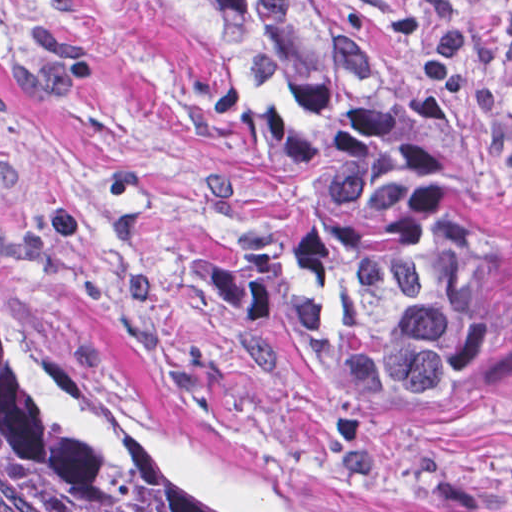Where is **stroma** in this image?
<instances>
[{
  "label": "stroma",
  "instance_id": "stroma-1",
  "mask_svg": "<svg viewBox=\"0 0 512 512\" xmlns=\"http://www.w3.org/2000/svg\"><path fill=\"white\" fill-rule=\"evenodd\" d=\"M323 1L512 269V0ZM243 58L208 0H0V265L38 364L215 512H512V378L402 435L281 311L312 221L217 123Z\"/></svg>",
  "mask_w": 512,
  "mask_h": 512
}]
</instances>
